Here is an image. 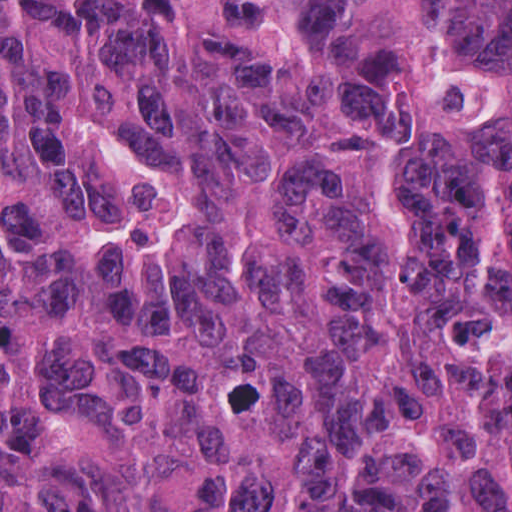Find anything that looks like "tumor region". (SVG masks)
<instances>
[{
  "instance_id": "e687c5a6",
  "label": "tumor region",
  "mask_w": 512,
  "mask_h": 512,
  "mask_svg": "<svg viewBox=\"0 0 512 512\" xmlns=\"http://www.w3.org/2000/svg\"><path fill=\"white\" fill-rule=\"evenodd\" d=\"M0 512H512V0H0Z\"/></svg>"
}]
</instances>
